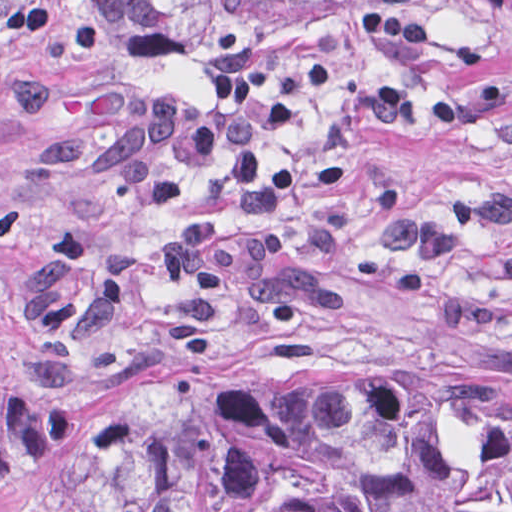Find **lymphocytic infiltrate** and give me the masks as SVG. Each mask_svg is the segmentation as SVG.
I'll return each mask as SVG.
<instances>
[{
  "label": "lymphocytic infiltrate",
  "instance_id": "lymphocytic-infiltrate-1",
  "mask_svg": "<svg viewBox=\"0 0 512 512\" xmlns=\"http://www.w3.org/2000/svg\"><path fill=\"white\" fill-rule=\"evenodd\" d=\"M335 78L328 62L307 73L282 76V93L268 90L253 75L215 77L205 104L198 107L181 103L170 92L158 93L146 112V149L126 166L121 197L142 211L176 209L186 194L184 181L157 168L156 154L167 152L186 168L198 170L224 153L222 188L230 206L253 219L277 218L296 171L291 165L263 168L258 135L297 126L309 95Z\"/></svg>",
  "mask_w": 512,
  "mask_h": 512
}]
</instances>
